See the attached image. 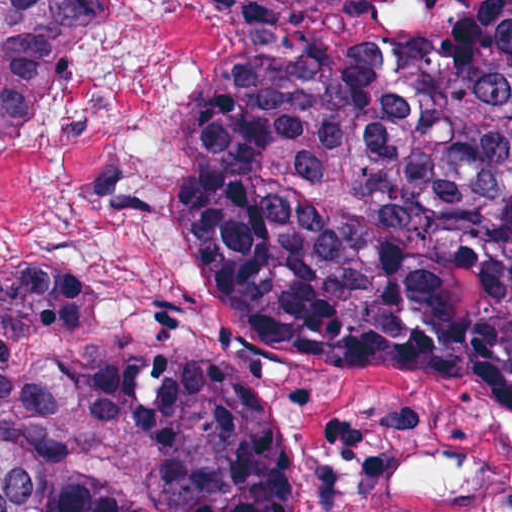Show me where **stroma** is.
<instances>
[{
    "instance_id": "obj_1",
    "label": "stroma",
    "mask_w": 512,
    "mask_h": 512,
    "mask_svg": "<svg viewBox=\"0 0 512 512\" xmlns=\"http://www.w3.org/2000/svg\"><path fill=\"white\" fill-rule=\"evenodd\" d=\"M219 1L218 35L280 27L364 1L512 0H0ZM221 307L217 343L198 353L235 370L282 429L293 512H512V386H464L371 376L320 365L259 334L204 271ZM62 277L37 269L0 279ZM127 351V350H125ZM128 352V351H127ZM130 353V352H129ZM144 512H170L149 462L107 480Z\"/></svg>"
}]
</instances>
